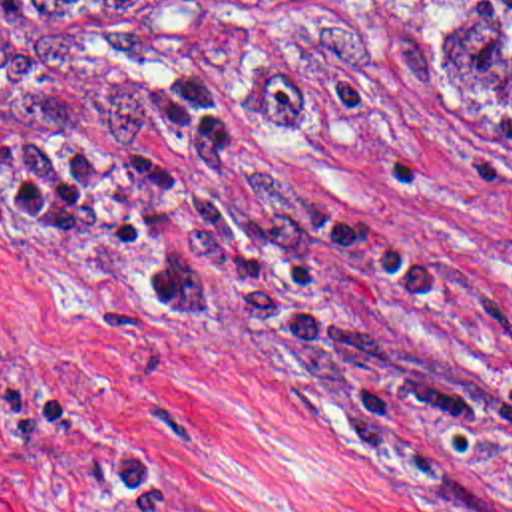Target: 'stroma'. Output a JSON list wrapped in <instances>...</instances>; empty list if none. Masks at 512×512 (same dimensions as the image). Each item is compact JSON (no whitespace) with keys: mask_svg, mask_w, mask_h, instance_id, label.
I'll use <instances>...</instances> for the list:
<instances>
[{"mask_svg":"<svg viewBox=\"0 0 512 512\" xmlns=\"http://www.w3.org/2000/svg\"><path fill=\"white\" fill-rule=\"evenodd\" d=\"M194 65L224 143L301 192L321 298L491 427L425 412L238 312L164 320L158 242L102 256L0 189V512H512V117L435 0H325L291 29L74 41L0 97Z\"/></svg>","mask_w":512,"mask_h":512,"instance_id":"stroma-1","label":"stroma"}]
</instances>
